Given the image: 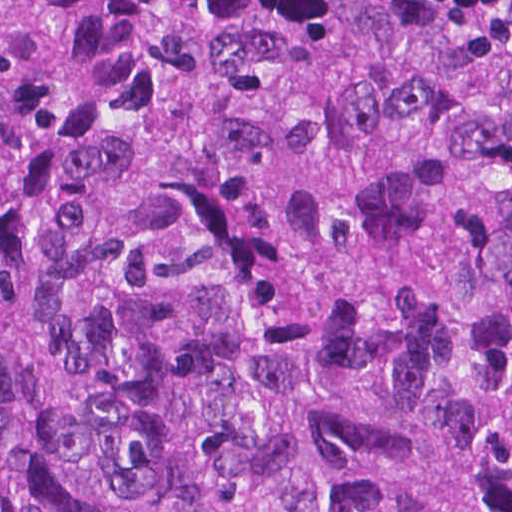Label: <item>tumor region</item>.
Here are the masks:
<instances>
[{"label": "tumor region", "instance_id": "obj_1", "mask_svg": "<svg viewBox=\"0 0 512 512\" xmlns=\"http://www.w3.org/2000/svg\"><path fill=\"white\" fill-rule=\"evenodd\" d=\"M0 512H512V0H0Z\"/></svg>", "mask_w": 512, "mask_h": 512}]
</instances>
